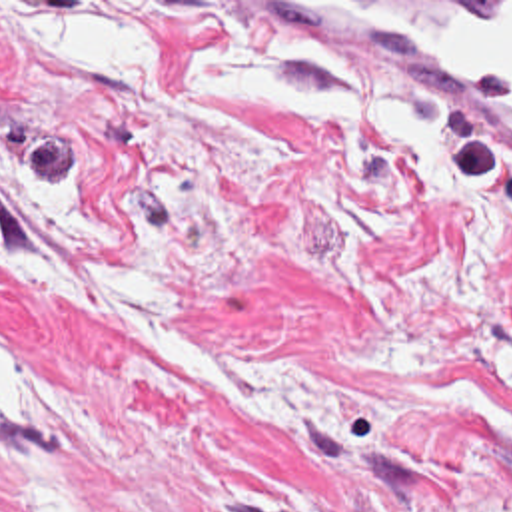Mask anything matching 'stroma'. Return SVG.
<instances>
[{
  "label": "stroma",
  "mask_w": 512,
  "mask_h": 512,
  "mask_svg": "<svg viewBox=\"0 0 512 512\" xmlns=\"http://www.w3.org/2000/svg\"><path fill=\"white\" fill-rule=\"evenodd\" d=\"M275 2L512 0H0V512H512V202L174 90Z\"/></svg>",
  "instance_id": "obj_1"
}]
</instances>
